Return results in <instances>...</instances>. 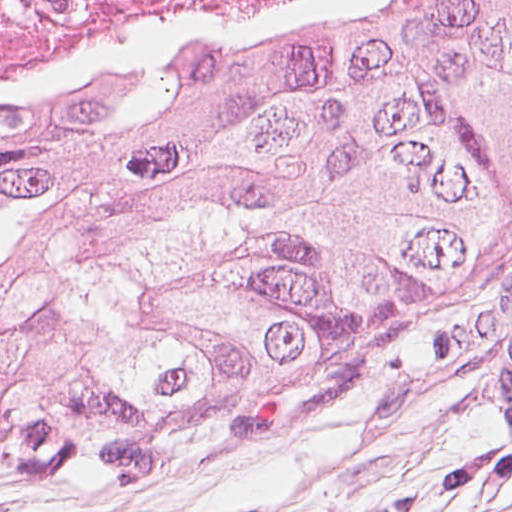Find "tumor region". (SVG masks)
Segmentation results:
<instances>
[{
  "label": "tumor region",
  "instance_id": "e687c5a6",
  "mask_svg": "<svg viewBox=\"0 0 512 512\" xmlns=\"http://www.w3.org/2000/svg\"><path fill=\"white\" fill-rule=\"evenodd\" d=\"M512 253V0L0 114V379L289 440Z\"/></svg>",
  "mask_w": 512,
  "mask_h": 512
}]
</instances>
